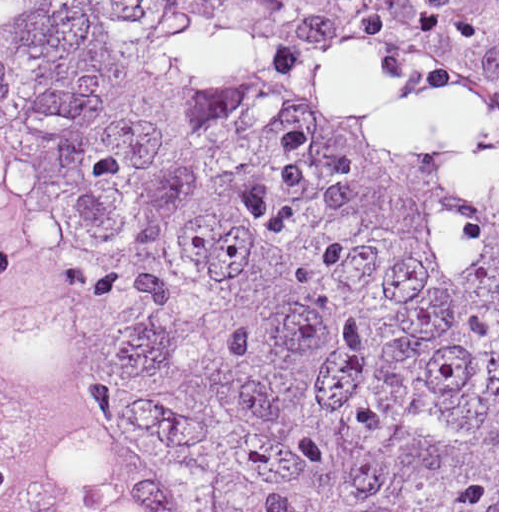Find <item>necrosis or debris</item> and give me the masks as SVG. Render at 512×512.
Listing matches in <instances>:
<instances>
[{"label":"necrosis or debris","mask_w":512,"mask_h":512,"mask_svg":"<svg viewBox=\"0 0 512 512\" xmlns=\"http://www.w3.org/2000/svg\"><path fill=\"white\" fill-rule=\"evenodd\" d=\"M0 512H152L107 375L74 336L1 291Z\"/></svg>","instance_id":"necrosis-or-debris-1"}]
</instances>
